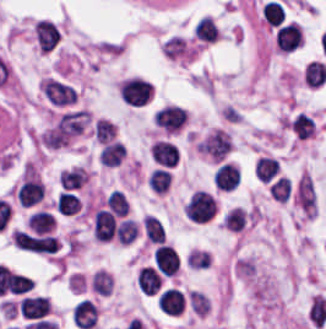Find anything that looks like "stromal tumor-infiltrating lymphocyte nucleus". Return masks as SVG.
I'll list each match as a JSON object with an SVG mask.
<instances>
[{
	"instance_id": "obj_1",
	"label": "stromal tumor-infiltrating lymphocyte nucleus",
	"mask_w": 326,
	"mask_h": 329,
	"mask_svg": "<svg viewBox=\"0 0 326 329\" xmlns=\"http://www.w3.org/2000/svg\"><path fill=\"white\" fill-rule=\"evenodd\" d=\"M154 126L160 131L175 133L182 129L188 120L187 110L181 105L165 103L155 109Z\"/></svg>"
},
{
	"instance_id": "obj_2",
	"label": "stromal tumor-infiltrating lymphocyte nucleus",
	"mask_w": 326,
	"mask_h": 329,
	"mask_svg": "<svg viewBox=\"0 0 326 329\" xmlns=\"http://www.w3.org/2000/svg\"><path fill=\"white\" fill-rule=\"evenodd\" d=\"M45 99L56 106H69L78 100L76 88L69 82L57 77H49L41 85Z\"/></svg>"
},
{
	"instance_id": "obj_3",
	"label": "stromal tumor-infiltrating lymphocyte nucleus",
	"mask_w": 326,
	"mask_h": 329,
	"mask_svg": "<svg viewBox=\"0 0 326 329\" xmlns=\"http://www.w3.org/2000/svg\"><path fill=\"white\" fill-rule=\"evenodd\" d=\"M217 210L214 196L204 190H197L185 206V214L193 221L213 219Z\"/></svg>"
},
{
	"instance_id": "obj_4",
	"label": "stromal tumor-infiltrating lymphocyte nucleus",
	"mask_w": 326,
	"mask_h": 329,
	"mask_svg": "<svg viewBox=\"0 0 326 329\" xmlns=\"http://www.w3.org/2000/svg\"><path fill=\"white\" fill-rule=\"evenodd\" d=\"M152 85L143 78H129L122 81L118 92L126 104L140 106L151 96Z\"/></svg>"
},
{
	"instance_id": "obj_5",
	"label": "stromal tumor-infiltrating lymphocyte nucleus",
	"mask_w": 326,
	"mask_h": 329,
	"mask_svg": "<svg viewBox=\"0 0 326 329\" xmlns=\"http://www.w3.org/2000/svg\"><path fill=\"white\" fill-rule=\"evenodd\" d=\"M241 171L231 162L219 160L212 174L213 185L219 191H232L240 181Z\"/></svg>"
},
{
	"instance_id": "obj_6",
	"label": "stromal tumor-infiltrating lymphocyte nucleus",
	"mask_w": 326,
	"mask_h": 329,
	"mask_svg": "<svg viewBox=\"0 0 326 329\" xmlns=\"http://www.w3.org/2000/svg\"><path fill=\"white\" fill-rule=\"evenodd\" d=\"M280 51H294L304 41L303 31L297 22H290L281 27L275 37Z\"/></svg>"
},
{
	"instance_id": "obj_7",
	"label": "stromal tumor-infiltrating lymphocyte nucleus",
	"mask_w": 326,
	"mask_h": 329,
	"mask_svg": "<svg viewBox=\"0 0 326 329\" xmlns=\"http://www.w3.org/2000/svg\"><path fill=\"white\" fill-rule=\"evenodd\" d=\"M184 294L178 288H165L156 298V305L166 314L178 315L183 308Z\"/></svg>"
},
{
	"instance_id": "obj_8",
	"label": "stromal tumor-infiltrating lymphocyte nucleus",
	"mask_w": 326,
	"mask_h": 329,
	"mask_svg": "<svg viewBox=\"0 0 326 329\" xmlns=\"http://www.w3.org/2000/svg\"><path fill=\"white\" fill-rule=\"evenodd\" d=\"M34 35L36 43L41 50L52 51L55 49L59 32L53 23L46 20H38L35 25Z\"/></svg>"
},
{
	"instance_id": "obj_9",
	"label": "stromal tumor-infiltrating lymphocyte nucleus",
	"mask_w": 326,
	"mask_h": 329,
	"mask_svg": "<svg viewBox=\"0 0 326 329\" xmlns=\"http://www.w3.org/2000/svg\"><path fill=\"white\" fill-rule=\"evenodd\" d=\"M49 301L44 295H25L20 312L29 319H42L48 314Z\"/></svg>"
},
{
	"instance_id": "obj_10",
	"label": "stromal tumor-infiltrating lymphocyte nucleus",
	"mask_w": 326,
	"mask_h": 329,
	"mask_svg": "<svg viewBox=\"0 0 326 329\" xmlns=\"http://www.w3.org/2000/svg\"><path fill=\"white\" fill-rule=\"evenodd\" d=\"M155 266L161 274L173 276L178 271L176 250L168 244H161L155 252Z\"/></svg>"
},
{
	"instance_id": "obj_11",
	"label": "stromal tumor-infiltrating lymphocyte nucleus",
	"mask_w": 326,
	"mask_h": 329,
	"mask_svg": "<svg viewBox=\"0 0 326 329\" xmlns=\"http://www.w3.org/2000/svg\"><path fill=\"white\" fill-rule=\"evenodd\" d=\"M116 222L109 211L99 209L93 223V234L101 241L112 240L115 233Z\"/></svg>"
},
{
	"instance_id": "obj_12",
	"label": "stromal tumor-infiltrating lymphocyte nucleus",
	"mask_w": 326,
	"mask_h": 329,
	"mask_svg": "<svg viewBox=\"0 0 326 329\" xmlns=\"http://www.w3.org/2000/svg\"><path fill=\"white\" fill-rule=\"evenodd\" d=\"M97 320V306L89 299H81L74 309L73 321L79 328L91 329Z\"/></svg>"
},
{
	"instance_id": "obj_13",
	"label": "stromal tumor-infiltrating lymphocyte nucleus",
	"mask_w": 326,
	"mask_h": 329,
	"mask_svg": "<svg viewBox=\"0 0 326 329\" xmlns=\"http://www.w3.org/2000/svg\"><path fill=\"white\" fill-rule=\"evenodd\" d=\"M220 28L216 21L209 15H202L198 21L193 37L198 43L209 44L216 40H219Z\"/></svg>"
},
{
	"instance_id": "obj_14",
	"label": "stromal tumor-infiltrating lymphocyte nucleus",
	"mask_w": 326,
	"mask_h": 329,
	"mask_svg": "<svg viewBox=\"0 0 326 329\" xmlns=\"http://www.w3.org/2000/svg\"><path fill=\"white\" fill-rule=\"evenodd\" d=\"M17 199L21 207H29L43 197V185L36 179H28L17 191Z\"/></svg>"
},
{
	"instance_id": "obj_15",
	"label": "stromal tumor-infiltrating lymphocyte nucleus",
	"mask_w": 326,
	"mask_h": 329,
	"mask_svg": "<svg viewBox=\"0 0 326 329\" xmlns=\"http://www.w3.org/2000/svg\"><path fill=\"white\" fill-rule=\"evenodd\" d=\"M137 283L144 295H155L162 285V280L152 266H145L137 272Z\"/></svg>"
},
{
	"instance_id": "obj_16",
	"label": "stromal tumor-infiltrating lymphocyte nucleus",
	"mask_w": 326,
	"mask_h": 329,
	"mask_svg": "<svg viewBox=\"0 0 326 329\" xmlns=\"http://www.w3.org/2000/svg\"><path fill=\"white\" fill-rule=\"evenodd\" d=\"M150 154L156 163L173 166L176 163L178 151L173 143L155 141L150 148Z\"/></svg>"
},
{
	"instance_id": "obj_17",
	"label": "stromal tumor-infiltrating lymphocyte nucleus",
	"mask_w": 326,
	"mask_h": 329,
	"mask_svg": "<svg viewBox=\"0 0 326 329\" xmlns=\"http://www.w3.org/2000/svg\"><path fill=\"white\" fill-rule=\"evenodd\" d=\"M303 79L309 88H322L326 84V65L311 61L303 70Z\"/></svg>"
},
{
	"instance_id": "obj_18",
	"label": "stromal tumor-infiltrating lymphocyte nucleus",
	"mask_w": 326,
	"mask_h": 329,
	"mask_svg": "<svg viewBox=\"0 0 326 329\" xmlns=\"http://www.w3.org/2000/svg\"><path fill=\"white\" fill-rule=\"evenodd\" d=\"M90 132L99 143L105 144L116 139V125L105 117H97Z\"/></svg>"
},
{
	"instance_id": "obj_19",
	"label": "stromal tumor-infiltrating lymphocyte nucleus",
	"mask_w": 326,
	"mask_h": 329,
	"mask_svg": "<svg viewBox=\"0 0 326 329\" xmlns=\"http://www.w3.org/2000/svg\"><path fill=\"white\" fill-rule=\"evenodd\" d=\"M247 218L245 210L236 206L231 207L225 212L220 225L228 231H242L246 226Z\"/></svg>"
},
{
	"instance_id": "obj_20",
	"label": "stromal tumor-infiltrating lymphocyte nucleus",
	"mask_w": 326,
	"mask_h": 329,
	"mask_svg": "<svg viewBox=\"0 0 326 329\" xmlns=\"http://www.w3.org/2000/svg\"><path fill=\"white\" fill-rule=\"evenodd\" d=\"M56 208L63 215H73L80 212L81 200L78 195L68 191H61L57 196Z\"/></svg>"
},
{
	"instance_id": "obj_21",
	"label": "stromal tumor-infiltrating lymphocyte nucleus",
	"mask_w": 326,
	"mask_h": 329,
	"mask_svg": "<svg viewBox=\"0 0 326 329\" xmlns=\"http://www.w3.org/2000/svg\"><path fill=\"white\" fill-rule=\"evenodd\" d=\"M27 224L36 234H46L54 226V218L51 212L40 209L29 218Z\"/></svg>"
},
{
	"instance_id": "obj_22",
	"label": "stromal tumor-infiltrating lymphocyte nucleus",
	"mask_w": 326,
	"mask_h": 329,
	"mask_svg": "<svg viewBox=\"0 0 326 329\" xmlns=\"http://www.w3.org/2000/svg\"><path fill=\"white\" fill-rule=\"evenodd\" d=\"M125 154V149L119 141H112L100 149V163L114 166L120 162Z\"/></svg>"
},
{
	"instance_id": "obj_23",
	"label": "stromal tumor-infiltrating lymphocyte nucleus",
	"mask_w": 326,
	"mask_h": 329,
	"mask_svg": "<svg viewBox=\"0 0 326 329\" xmlns=\"http://www.w3.org/2000/svg\"><path fill=\"white\" fill-rule=\"evenodd\" d=\"M142 226L148 240L158 244L165 242V230L158 219L152 216H145Z\"/></svg>"
},
{
	"instance_id": "obj_24",
	"label": "stromal tumor-infiltrating lymphocyte nucleus",
	"mask_w": 326,
	"mask_h": 329,
	"mask_svg": "<svg viewBox=\"0 0 326 329\" xmlns=\"http://www.w3.org/2000/svg\"><path fill=\"white\" fill-rule=\"evenodd\" d=\"M86 174L78 167L62 170L59 173V185L68 189L78 188L85 180Z\"/></svg>"
},
{
	"instance_id": "obj_25",
	"label": "stromal tumor-infiltrating lymphocyte nucleus",
	"mask_w": 326,
	"mask_h": 329,
	"mask_svg": "<svg viewBox=\"0 0 326 329\" xmlns=\"http://www.w3.org/2000/svg\"><path fill=\"white\" fill-rule=\"evenodd\" d=\"M106 207L117 217H124L128 211L129 203L123 193L112 191L105 200Z\"/></svg>"
},
{
	"instance_id": "obj_26",
	"label": "stromal tumor-infiltrating lymphocyte nucleus",
	"mask_w": 326,
	"mask_h": 329,
	"mask_svg": "<svg viewBox=\"0 0 326 329\" xmlns=\"http://www.w3.org/2000/svg\"><path fill=\"white\" fill-rule=\"evenodd\" d=\"M171 183V175L166 169L154 168L149 174L148 184L153 191L165 192Z\"/></svg>"
},
{
	"instance_id": "obj_27",
	"label": "stromal tumor-infiltrating lymphocyte nucleus",
	"mask_w": 326,
	"mask_h": 329,
	"mask_svg": "<svg viewBox=\"0 0 326 329\" xmlns=\"http://www.w3.org/2000/svg\"><path fill=\"white\" fill-rule=\"evenodd\" d=\"M138 234L136 223L132 219H125L115 228V236L117 241L131 243Z\"/></svg>"
},
{
	"instance_id": "obj_28",
	"label": "stromal tumor-infiltrating lymphocyte nucleus",
	"mask_w": 326,
	"mask_h": 329,
	"mask_svg": "<svg viewBox=\"0 0 326 329\" xmlns=\"http://www.w3.org/2000/svg\"><path fill=\"white\" fill-rule=\"evenodd\" d=\"M278 162L272 158L260 157L255 163V174L261 181H270L276 172Z\"/></svg>"
},
{
	"instance_id": "obj_29",
	"label": "stromal tumor-infiltrating lymphocyte nucleus",
	"mask_w": 326,
	"mask_h": 329,
	"mask_svg": "<svg viewBox=\"0 0 326 329\" xmlns=\"http://www.w3.org/2000/svg\"><path fill=\"white\" fill-rule=\"evenodd\" d=\"M263 16L267 25L279 26L284 21V8L279 2L269 1L264 8Z\"/></svg>"
},
{
	"instance_id": "obj_30",
	"label": "stromal tumor-infiltrating lymphocyte nucleus",
	"mask_w": 326,
	"mask_h": 329,
	"mask_svg": "<svg viewBox=\"0 0 326 329\" xmlns=\"http://www.w3.org/2000/svg\"><path fill=\"white\" fill-rule=\"evenodd\" d=\"M290 124L294 131L303 138L315 132L316 123L313 118L301 112Z\"/></svg>"
},
{
	"instance_id": "obj_31",
	"label": "stromal tumor-infiltrating lymphocyte nucleus",
	"mask_w": 326,
	"mask_h": 329,
	"mask_svg": "<svg viewBox=\"0 0 326 329\" xmlns=\"http://www.w3.org/2000/svg\"><path fill=\"white\" fill-rule=\"evenodd\" d=\"M291 183L289 179L279 178L273 182L269 194L274 201H288Z\"/></svg>"
}]
</instances>
